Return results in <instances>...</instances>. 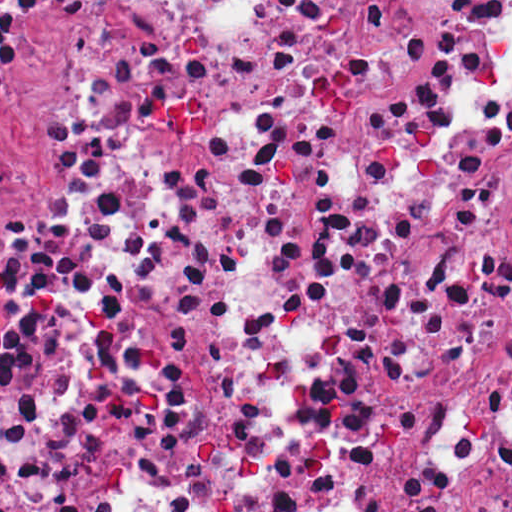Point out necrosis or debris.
Listing matches in <instances>:
<instances>
[{"label":"necrosis or debris","mask_w":512,"mask_h":512,"mask_svg":"<svg viewBox=\"0 0 512 512\" xmlns=\"http://www.w3.org/2000/svg\"><path fill=\"white\" fill-rule=\"evenodd\" d=\"M0 512H512V0H0Z\"/></svg>","instance_id":"1"}]
</instances>
